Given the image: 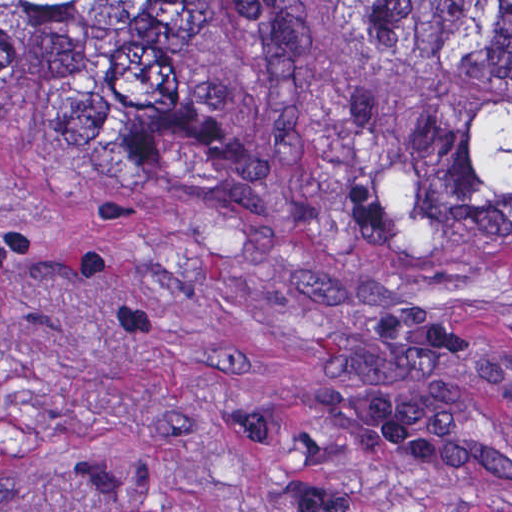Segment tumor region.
I'll list each match as a JSON object with an SVG mask.
<instances>
[{
  "mask_svg": "<svg viewBox=\"0 0 512 512\" xmlns=\"http://www.w3.org/2000/svg\"><path fill=\"white\" fill-rule=\"evenodd\" d=\"M423 97L424 158L488 255L512 252V0H360ZM0 128L138 191L228 176L181 37L142 0H0Z\"/></svg>",
  "mask_w": 512,
  "mask_h": 512,
  "instance_id": "obj_1",
  "label": "tumor region"
}]
</instances>
